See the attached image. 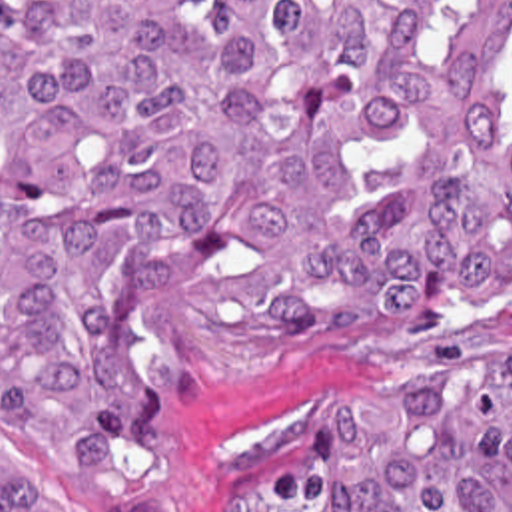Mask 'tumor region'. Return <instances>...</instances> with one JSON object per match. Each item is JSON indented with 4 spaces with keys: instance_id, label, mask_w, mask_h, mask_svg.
<instances>
[{
    "instance_id": "tumor-region-1",
    "label": "tumor region",
    "mask_w": 512,
    "mask_h": 512,
    "mask_svg": "<svg viewBox=\"0 0 512 512\" xmlns=\"http://www.w3.org/2000/svg\"><path fill=\"white\" fill-rule=\"evenodd\" d=\"M511 280L512 0H0V512H157L181 378ZM199 512H512V352Z\"/></svg>"
}]
</instances>
